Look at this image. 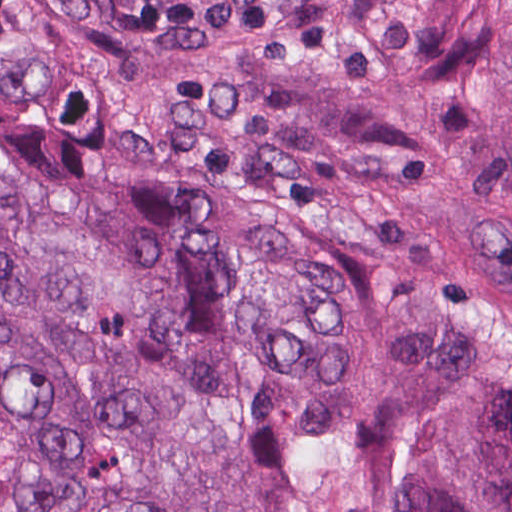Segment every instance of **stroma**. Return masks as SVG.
Here are the masks:
<instances>
[{
	"instance_id": "obj_1",
	"label": "stroma",
	"mask_w": 512,
	"mask_h": 512,
	"mask_svg": "<svg viewBox=\"0 0 512 512\" xmlns=\"http://www.w3.org/2000/svg\"><path fill=\"white\" fill-rule=\"evenodd\" d=\"M287 1H267L179 356L186 378L199 400L236 241Z\"/></svg>"
}]
</instances>
